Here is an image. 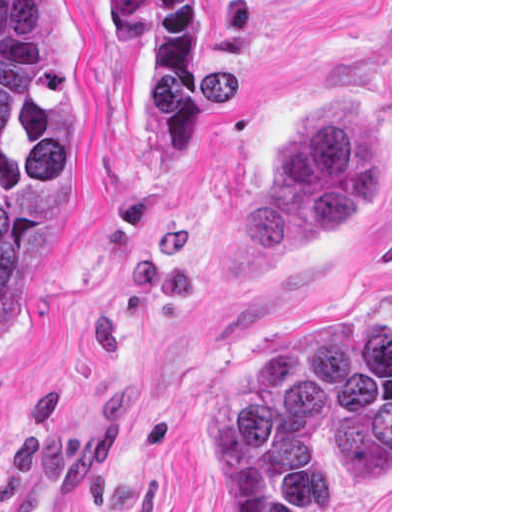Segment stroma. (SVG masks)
Returning a JSON list of instances; mask_svg holds the SVG:
<instances>
[{
    "label": "stroma",
    "instance_id": "stroma-1",
    "mask_svg": "<svg viewBox=\"0 0 512 512\" xmlns=\"http://www.w3.org/2000/svg\"><path fill=\"white\" fill-rule=\"evenodd\" d=\"M66 1L81 105L52 172V247L0 343V506L75 440L87 479L71 512H219L212 393L239 352L301 319L390 312V489L310 457L304 512H392V0ZM96 1H208L198 139L169 172L140 69ZM363 107L381 142L364 219L225 280L219 244L310 113Z\"/></svg>",
    "mask_w": 512,
    "mask_h": 512
}]
</instances>
